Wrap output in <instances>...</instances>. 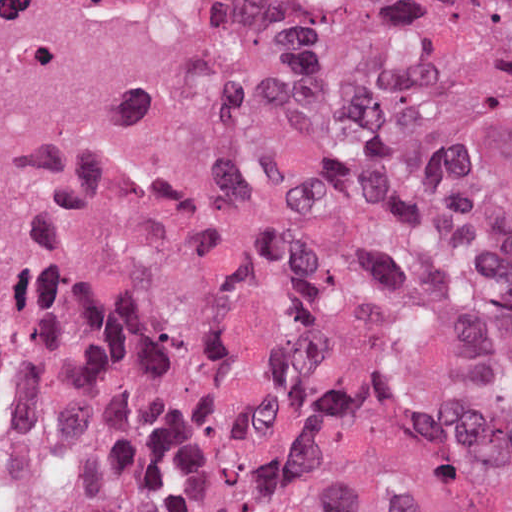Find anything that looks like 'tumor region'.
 <instances>
[{
	"label": "tumor region",
	"instance_id": "obj_1",
	"mask_svg": "<svg viewBox=\"0 0 512 512\" xmlns=\"http://www.w3.org/2000/svg\"><path fill=\"white\" fill-rule=\"evenodd\" d=\"M271 144L0 340V512H512V0H239Z\"/></svg>",
	"mask_w": 512,
	"mask_h": 512
}]
</instances>
